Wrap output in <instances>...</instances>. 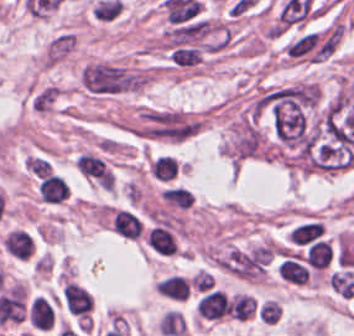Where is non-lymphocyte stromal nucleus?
Returning a JSON list of instances; mask_svg holds the SVG:
<instances>
[{
  "label": "non-lymphocyte stromal nucleus",
  "instance_id": "dd21d789",
  "mask_svg": "<svg viewBox=\"0 0 354 336\" xmlns=\"http://www.w3.org/2000/svg\"><path fill=\"white\" fill-rule=\"evenodd\" d=\"M82 86L93 93H119L135 90L145 79L142 71L120 64L88 63L80 76Z\"/></svg>",
  "mask_w": 354,
  "mask_h": 336
},
{
  "label": "non-lymphocyte stromal nucleus",
  "instance_id": "a72fc3eb",
  "mask_svg": "<svg viewBox=\"0 0 354 336\" xmlns=\"http://www.w3.org/2000/svg\"><path fill=\"white\" fill-rule=\"evenodd\" d=\"M169 55L178 67H197L204 53L199 45L185 41L170 47Z\"/></svg>",
  "mask_w": 354,
  "mask_h": 336
},
{
  "label": "non-lymphocyte stromal nucleus",
  "instance_id": "3746e769",
  "mask_svg": "<svg viewBox=\"0 0 354 336\" xmlns=\"http://www.w3.org/2000/svg\"><path fill=\"white\" fill-rule=\"evenodd\" d=\"M75 44V35L70 32H62L50 41L46 58L49 62H56L67 55Z\"/></svg>",
  "mask_w": 354,
  "mask_h": 336
},
{
  "label": "non-lymphocyte stromal nucleus",
  "instance_id": "fc2b8d12",
  "mask_svg": "<svg viewBox=\"0 0 354 336\" xmlns=\"http://www.w3.org/2000/svg\"><path fill=\"white\" fill-rule=\"evenodd\" d=\"M58 89L52 84H45L34 92L31 104L35 109H49Z\"/></svg>",
  "mask_w": 354,
  "mask_h": 336
}]
</instances>
